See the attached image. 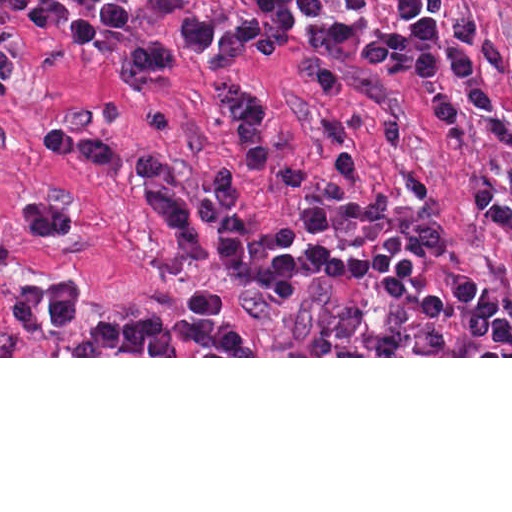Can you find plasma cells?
Here are the masks:
<instances>
[{
    "label": "plasma cells",
    "mask_w": 512,
    "mask_h": 512,
    "mask_svg": "<svg viewBox=\"0 0 512 512\" xmlns=\"http://www.w3.org/2000/svg\"><path fill=\"white\" fill-rule=\"evenodd\" d=\"M279 35L293 33L301 12L323 16L329 0H246ZM357 9L364 0H344ZM25 10L29 26L47 30L67 24L76 49L90 55L100 22L125 25L129 13L119 0H0ZM394 19L411 38H430L438 22L412 0H394ZM136 197L152 203L188 256L215 266L241 284L263 288L277 299H305L306 275L298 263V232L285 223H254L224 214L214 201L189 193L168 196L154 184L135 183ZM217 290L202 289L186 317L142 316L95 323L72 342L71 356H257L254 335L221 320Z\"/></svg>",
    "instance_id": "obj_1"
}]
</instances>
